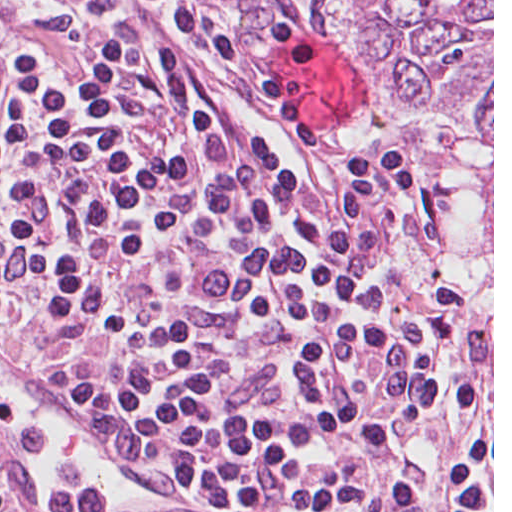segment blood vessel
Segmentation results:
<instances>
[{"mask_svg":"<svg viewBox=\"0 0 512 512\" xmlns=\"http://www.w3.org/2000/svg\"><path fill=\"white\" fill-rule=\"evenodd\" d=\"M0 385L13 389L65 424L80 441L137 487L133 499L115 496L68 499L59 504L58 512H117L198 486L178 466L82 412L54 375L40 384H33L0 367Z\"/></svg>","mask_w":512,"mask_h":512,"instance_id":"8fb6f2fc","label":"blood vessel"}]
</instances>
